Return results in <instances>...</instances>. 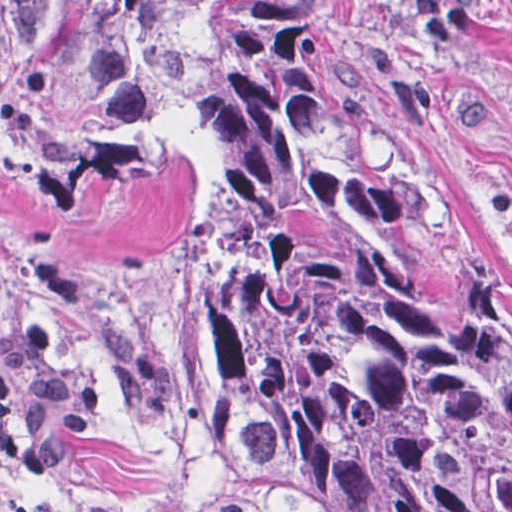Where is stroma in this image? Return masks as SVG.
Wrapping results in <instances>:
<instances>
[{"mask_svg": "<svg viewBox=\"0 0 512 512\" xmlns=\"http://www.w3.org/2000/svg\"><path fill=\"white\" fill-rule=\"evenodd\" d=\"M32 0H0L18 12ZM512 290V0H341L329 80ZM291 512L149 426H105L52 467L0 454V512Z\"/></svg>", "mask_w": 512, "mask_h": 512, "instance_id": "obj_1", "label": "stroma"}]
</instances>
